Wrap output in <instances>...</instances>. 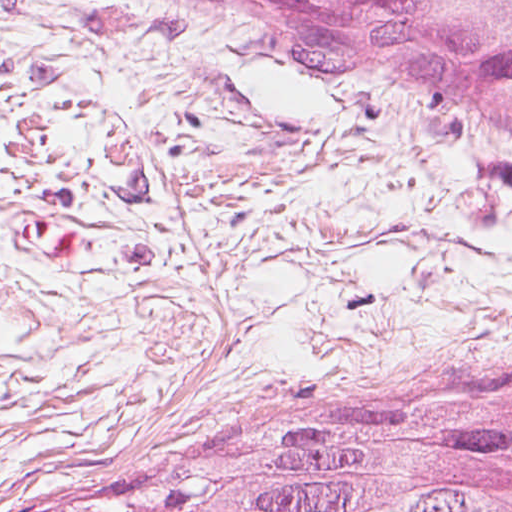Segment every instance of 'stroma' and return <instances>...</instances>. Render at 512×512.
Here are the masks:
<instances>
[{"instance_id": "stroma-1", "label": "stroma", "mask_w": 512, "mask_h": 512, "mask_svg": "<svg viewBox=\"0 0 512 512\" xmlns=\"http://www.w3.org/2000/svg\"><path fill=\"white\" fill-rule=\"evenodd\" d=\"M512 396V140L208 0H0V512Z\"/></svg>"}]
</instances>
